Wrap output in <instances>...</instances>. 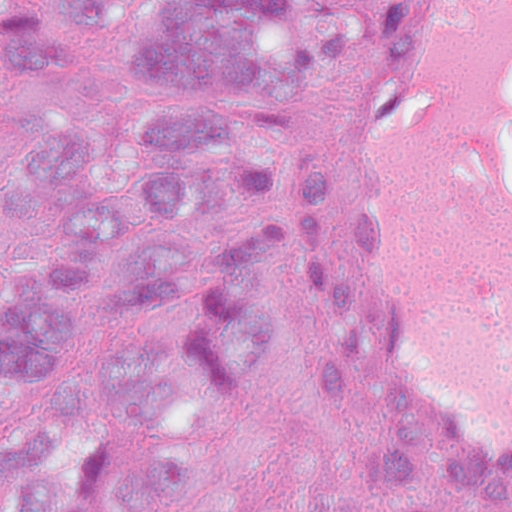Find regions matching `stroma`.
I'll list each match as a JSON object with an SVG mask.
<instances>
[{
	"label": "stroma",
	"mask_w": 512,
	"mask_h": 512,
	"mask_svg": "<svg viewBox=\"0 0 512 512\" xmlns=\"http://www.w3.org/2000/svg\"><path fill=\"white\" fill-rule=\"evenodd\" d=\"M150 1L136 0L135 9ZM389 1L361 0L371 23L363 43L341 71L316 77L300 101L310 111L306 133L288 134L272 160L281 222L267 277L270 332L187 431L234 461L239 512L272 510L307 451L331 445H409L479 501L512 512V462L463 443L396 399L358 316L347 198L361 121L379 81ZM133 54L128 18L90 28L85 62L102 82Z\"/></svg>",
	"instance_id": "obj_1"
}]
</instances>
